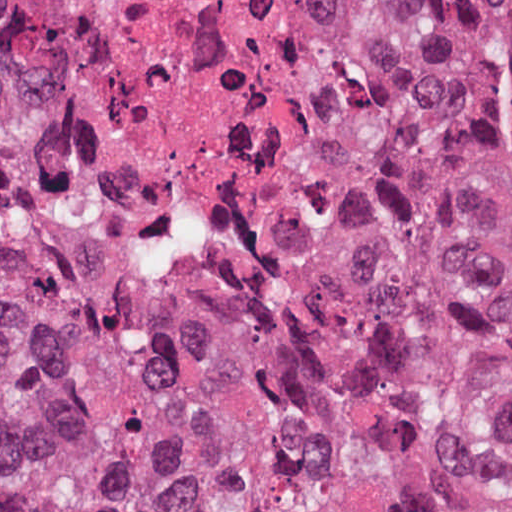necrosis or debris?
Returning a JSON list of instances; mask_svg holds the SVG:
<instances>
[{
	"label": "necrosis or debris",
	"instance_id": "4bbe7bcc",
	"mask_svg": "<svg viewBox=\"0 0 512 512\" xmlns=\"http://www.w3.org/2000/svg\"><path fill=\"white\" fill-rule=\"evenodd\" d=\"M346 0H0L25 155L260 312L512 358V299L318 243L304 224Z\"/></svg>",
	"mask_w": 512,
	"mask_h": 512
}]
</instances>
